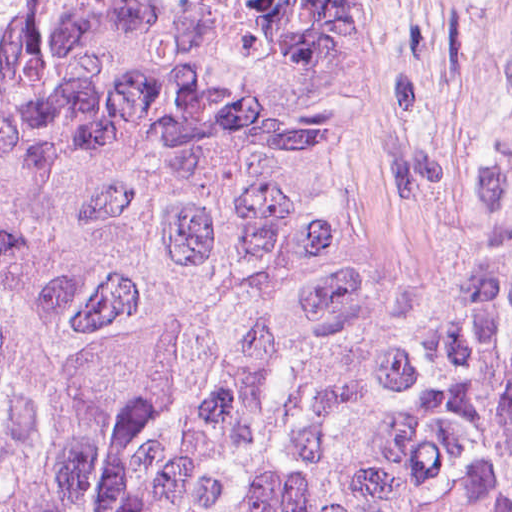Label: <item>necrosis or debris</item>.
I'll return each instance as SVG.
<instances>
[{
    "mask_svg": "<svg viewBox=\"0 0 512 512\" xmlns=\"http://www.w3.org/2000/svg\"><path fill=\"white\" fill-rule=\"evenodd\" d=\"M306 27L346 220L396 261H438L512 115V0H275Z\"/></svg>",
    "mask_w": 512,
    "mask_h": 512,
    "instance_id": "4bbe7bcc",
    "label": "necrosis or debris"
}]
</instances>
